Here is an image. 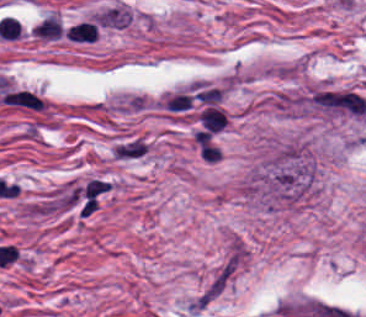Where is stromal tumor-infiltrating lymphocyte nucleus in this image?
<instances>
[{
  "mask_svg": "<svg viewBox=\"0 0 366 317\" xmlns=\"http://www.w3.org/2000/svg\"><path fill=\"white\" fill-rule=\"evenodd\" d=\"M34 34L38 38L56 39L60 34L58 17L54 13H47L33 24Z\"/></svg>",
  "mask_w": 366,
  "mask_h": 317,
  "instance_id": "obj_2",
  "label": "stromal tumor-infiltrating lymphocyte nucleus"
},
{
  "mask_svg": "<svg viewBox=\"0 0 366 317\" xmlns=\"http://www.w3.org/2000/svg\"><path fill=\"white\" fill-rule=\"evenodd\" d=\"M65 35L72 41L91 43L97 35V26L89 19H81L71 25Z\"/></svg>",
  "mask_w": 366,
  "mask_h": 317,
  "instance_id": "obj_1",
  "label": "stromal tumor-infiltrating lymphocyte nucleus"
}]
</instances>
